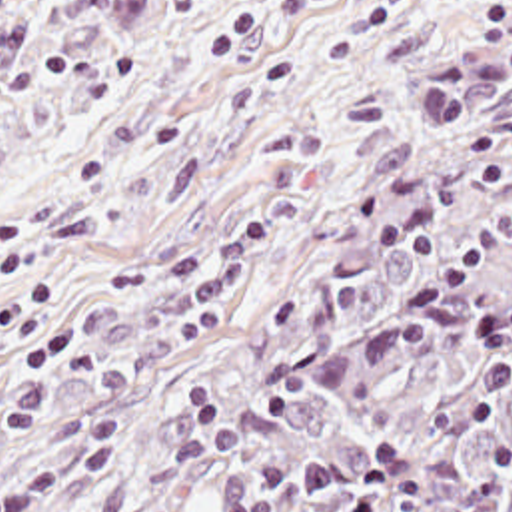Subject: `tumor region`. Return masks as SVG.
<instances>
[{
  "mask_svg": "<svg viewBox=\"0 0 512 512\" xmlns=\"http://www.w3.org/2000/svg\"><path fill=\"white\" fill-rule=\"evenodd\" d=\"M47 512H512V69L321 165L165 412Z\"/></svg>",
  "mask_w": 512,
  "mask_h": 512,
  "instance_id": "obj_1",
  "label": "tumor region"
}]
</instances>
